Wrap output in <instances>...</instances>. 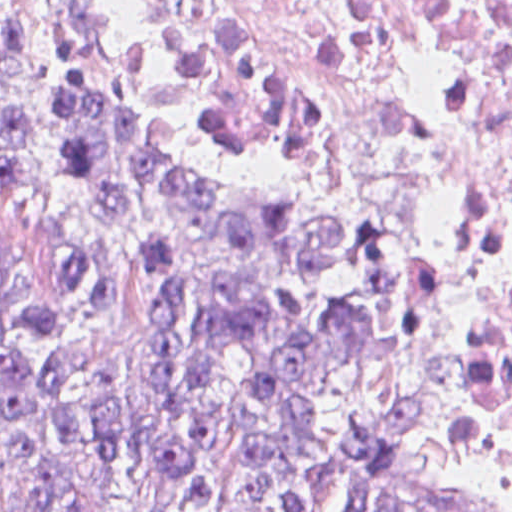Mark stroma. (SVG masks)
I'll return each mask as SVG.
<instances>
[{
	"instance_id": "35a3bbf8",
	"label": "stroma",
	"mask_w": 512,
	"mask_h": 512,
	"mask_svg": "<svg viewBox=\"0 0 512 512\" xmlns=\"http://www.w3.org/2000/svg\"><path fill=\"white\" fill-rule=\"evenodd\" d=\"M125 88L166 142L177 162L194 175L264 214L304 233L352 240L318 195L286 164L235 144L207 140L162 124L115 38L94 5L69 0ZM438 312L455 351L459 419L442 430L430 473L458 498L495 512H512L486 470V406L456 332L438 298ZM322 512H354L339 476Z\"/></svg>"
}]
</instances>
